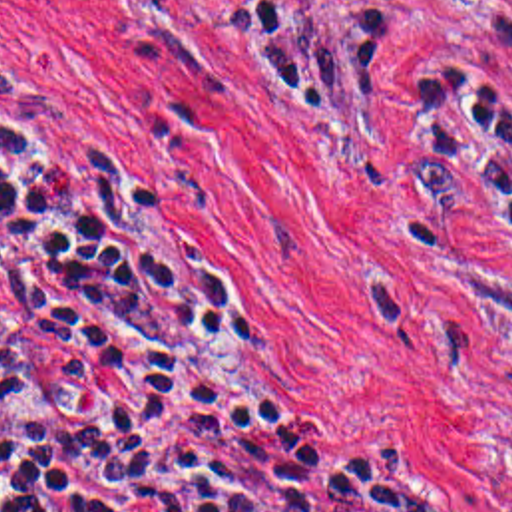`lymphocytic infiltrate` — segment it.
<instances>
[{"instance_id": "lymphocytic-infiltrate-1", "label": "lymphocytic infiltrate", "mask_w": 512, "mask_h": 512, "mask_svg": "<svg viewBox=\"0 0 512 512\" xmlns=\"http://www.w3.org/2000/svg\"><path fill=\"white\" fill-rule=\"evenodd\" d=\"M233 3L267 101L367 99L385 41ZM482 23L512 59V13ZM419 126L415 166L512 246V109L431 67ZM0 512L461 511L283 399L0 61Z\"/></svg>"}]
</instances>
